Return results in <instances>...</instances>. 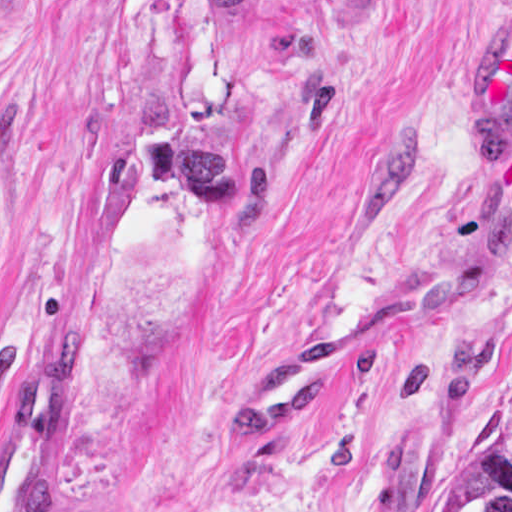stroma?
<instances>
[{"mask_svg":"<svg viewBox=\"0 0 512 512\" xmlns=\"http://www.w3.org/2000/svg\"><path fill=\"white\" fill-rule=\"evenodd\" d=\"M511 0H0V436L70 338L45 512H432L512 384ZM428 317L261 442L225 409L324 319Z\"/></svg>","mask_w":512,"mask_h":512,"instance_id":"35a3bbf8","label":"stroma"}]
</instances>
